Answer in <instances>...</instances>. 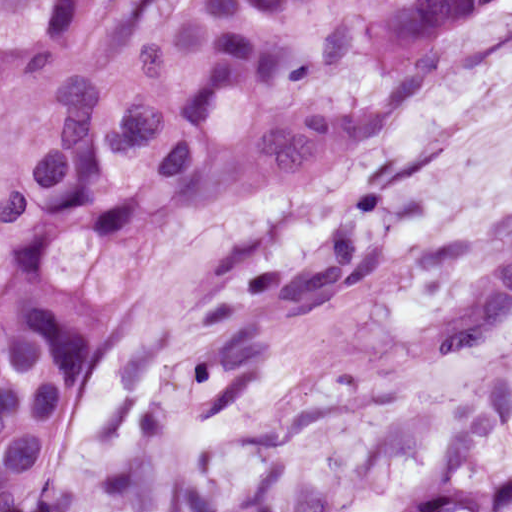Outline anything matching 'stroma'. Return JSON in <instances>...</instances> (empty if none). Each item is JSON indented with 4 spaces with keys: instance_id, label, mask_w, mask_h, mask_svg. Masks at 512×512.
Here are the masks:
<instances>
[{
    "instance_id": "obj_1",
    "label": "stroma",
    "mask_w": 512,
    "mask_h": 512,
    "mask_svg": "<svg viewBox=\"0 0 512 512\" xmlns=\"http://www.w3.org/2000/svg\"><path fill=\"white\" fill-rule=\"evenodd\" d=\"M66 86L63 70L0 102V280L8 190ZM511 196L512 0H496L359 154L228 201L156 247L106 377Z\"/></svg>"
}]
</instances>
